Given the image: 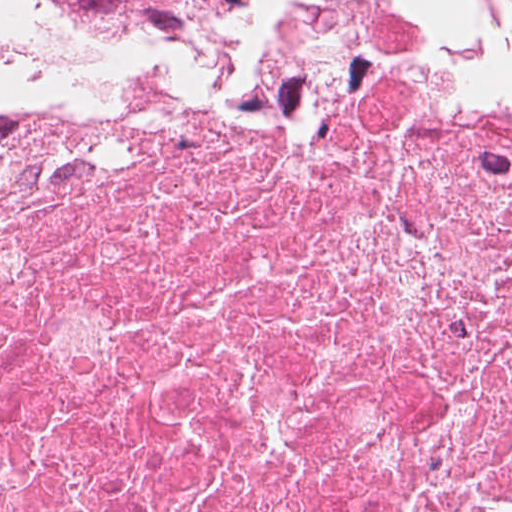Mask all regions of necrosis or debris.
<instances>
[{
	"label": "necrosis or debris",
	"mask_w": 512,
	"mask_h": 512,
	"mask_svg": "<svg viewBox=\"0 0 512 512\" xmlns=\"http://www.w3.org/2000/svg\"><path fill=\"white\" fill-rule=\"evenodd\" d=\"M455 1L0 89V512H347Z\"/></svg>",
	"instance_id": "necrosis-or-debris-1"
}]
</instances>
